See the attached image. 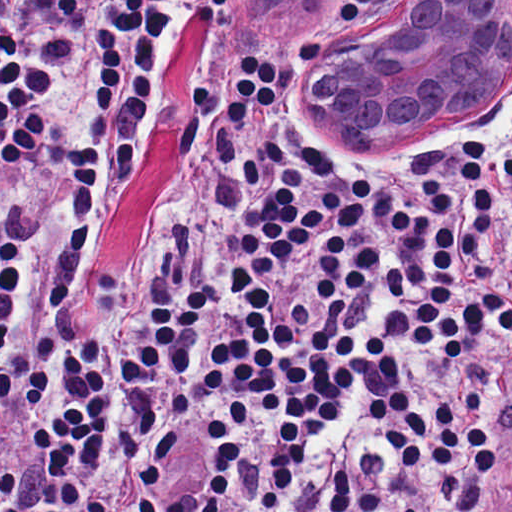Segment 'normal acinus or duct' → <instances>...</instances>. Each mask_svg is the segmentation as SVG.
Returning <instances> with one entry per match:
<instances>
[{"mask_svg": "<svg viewBox=\"0 0 512 512\" xmlns=\"http://www.w3.org/2000/svg\"><path fill=\"white\" fill-rule=\"evenodd\" d=\"M319 111L367 146L457 143L512 101V0H392L342 50Z\"/></svg>", "mask_w": 512, "mask_h": 512, "instance_id": "normal-acinus-or-duct-1", "label": "normal acinus or duct"}]
</instances>
